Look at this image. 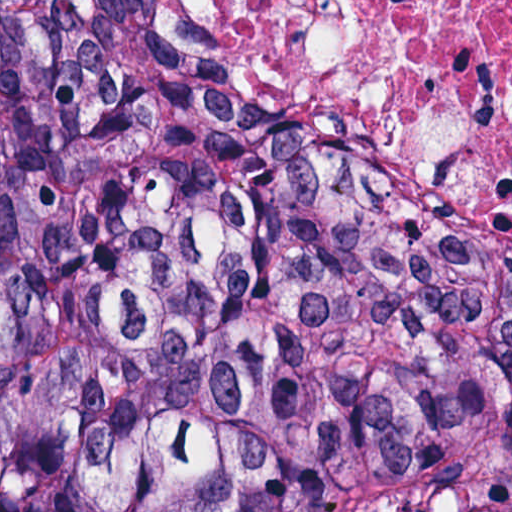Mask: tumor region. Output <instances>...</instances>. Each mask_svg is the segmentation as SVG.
Returning <instances> with one entry per match:
<instances>
[{
    "instance_id": "1",
    "label": "tumor region",
    "mask_w": 512,
    "mask_h": 512,
    "mask_svg": "<svg viewBox=\"0 0 512 512\" xmlns=\"http://www.w3.org/2000/svg\"><path fill=\"white\" fill-rule=\"evenodd\" d=\"M0 512H512V265L131 0H0Z\"/></svg>"
}]
</instances>
